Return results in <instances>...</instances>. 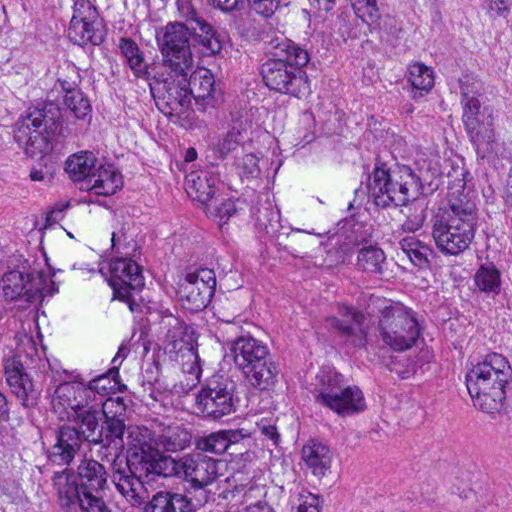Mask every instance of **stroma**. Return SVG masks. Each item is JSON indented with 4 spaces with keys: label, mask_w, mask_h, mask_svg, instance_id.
<instances>
[{
    "label": "stroma",
    "mask_w": 512,
    "mask_h": 512,
    "mask_svg": "<svg viewBox=\"0 0 512 512\" xmlns=\"http://www.w3.org/2000/svg\"><path fill=\"white\" fill-rule=\"evenodd\" d=\"M130 235L151 262L240 288L291 335L374 367L381 406L355 443L331 512H512V381L492 387L449 345L281 250L164 215H141Z\"/></svg>",
    "instance_id": "obj_1"
}]
</instances>
